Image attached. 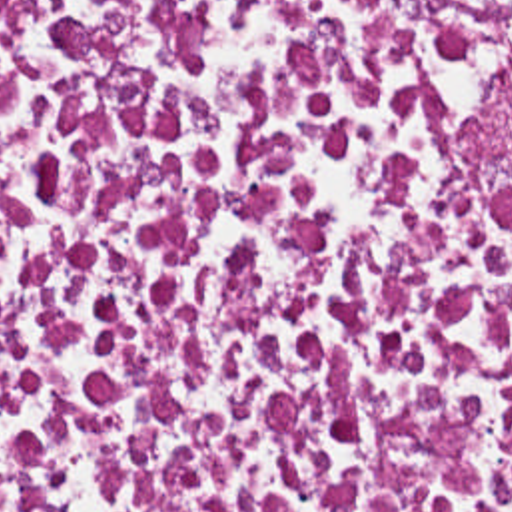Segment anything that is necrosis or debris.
Instances as JSON below:
<instances>
[{
  "instance_id": "necrosis-or-debris-1",
  "label": "necrosis or debris",
  "mask_w": 512,
  "mask_h": 512,
  "mask_svg": "<svg viewBox=\"0 0 512 512\" xmlns=\"http://www.w3.org/2000/svg\"><path fill=\"white\" fill-rule=\"evenodd\" d=\"M0 512H512V0H0Z\"/></svg>"
}]
</instances>
